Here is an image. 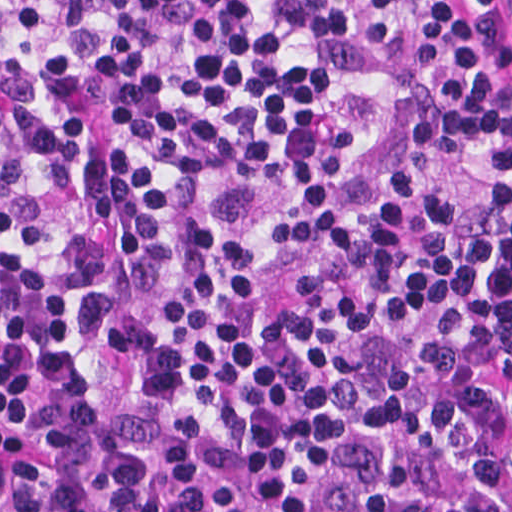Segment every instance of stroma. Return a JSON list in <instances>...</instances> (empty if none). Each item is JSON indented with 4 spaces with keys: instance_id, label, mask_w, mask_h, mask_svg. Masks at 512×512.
Returning a JSON list of instances; mask_svg holds the SVG:
<instances>
[{
    "instance_id": "1",
    "label": "stroma",
    "mask_w": 512,
    "mask_h": 512,
    "mask_svg": "<svg viewBox=\"0 0 512 512\" xmlns=\"http://www.w3.org/2000/svg\"><path fill=\"white\" fill-rule=\"evenodd\" d=\"M451 3L465 5L495 18L504 35L505 48L512 54V0H446ZM504 247V244L498 234ZM504 252L512 267L511 260Z\"/></svg>"
}]
</instances>
